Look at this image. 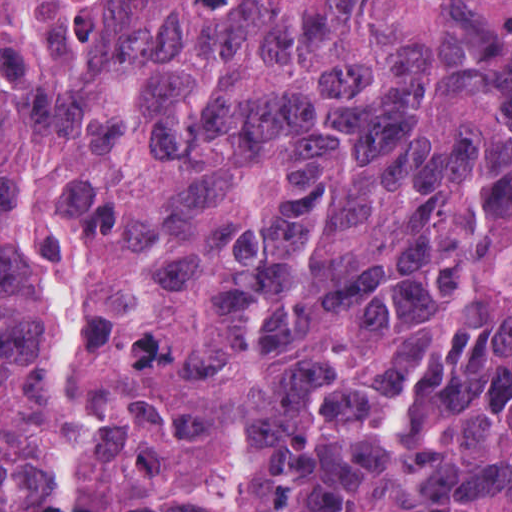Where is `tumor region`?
<instances>
[{
	"label": "tumor region",
	"instance_id": "tumor-region-1",
	"mask_svg": "<svg viewBox=\"0 0 512 512\" xmlns=\"http://www.w3.org/2000/svg\"><path fill=\"white\" fill-rule=\"evenodd\" d=\"M0 204L79 512L509 511L512 0H0ZM59 461L0 231V512Z\"/></svg>",
	"mask_w": 512,
	"mask_h": 512
}]
</instances>
